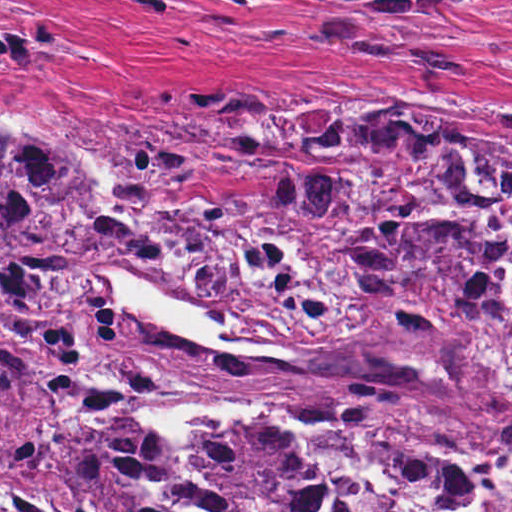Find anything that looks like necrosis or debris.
<instances>
[{
  "instance_id": "obj_1",
  "label": "necrosis or debris",
  "mask_w": 512,
  "mask_h": 512,
  "mask_svg": "<svg viewBox=\"0 0 512 512\" xmlns=\"http://www.w3.org/2000/svg\"><path fill=\"white\" fill-rule=\"evenodd\" d=\"M300 138L354 171H289L209 211L167 216L150 251L237 325L336 341L357 334L354 259L408 288L467 297L479 335L512 349V193L428 128L333 112ZM202 437L280 450L338 512H512V457L398 446L345 425L265 413Z\"/></svg>"
}]
</instances>
